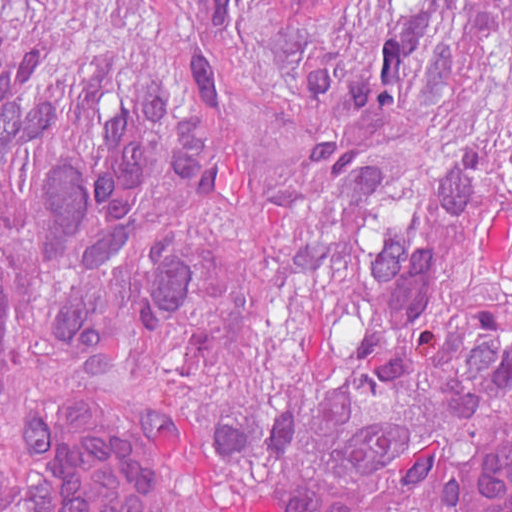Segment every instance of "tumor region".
Returning <instances> with one entry per match:
<instances>
[{"label":"tumor region","mask_w":512,"mask_h":512,"mask_svg":"<svg viewBox=\"0 0 512 512\" xmlns=\"http://www.w3.org/2000/svg\"><path fill=\"white\" fill-rule=\"evenodd\" d=\"M83 390L164 512H512V0H0V512Z\"/></svg>","instance_id":"e687c5a6"}]
</instances>
